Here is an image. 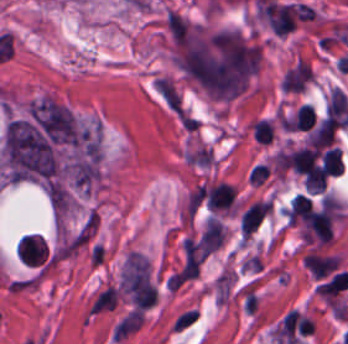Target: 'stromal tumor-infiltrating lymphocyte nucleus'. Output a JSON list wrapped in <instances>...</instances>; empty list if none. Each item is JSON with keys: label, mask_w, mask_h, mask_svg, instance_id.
Returning <instances> with one entry per match:
<instances>
[{"label": "stromal tumor-infiltrating lymphocyte nucleus", "mask_w": 348, "mask_h": 344, "mask_svg": "<svg viewBox=\"0 0 348 344\" xmlns=\"http://www.w3.org/2000/svg\"><path fill=\"white\" fill-rule=\"evenodd\" d=\"M253 137L260 143H268L273 138V126L266 118H258L252 128Z\"/></svg>", "instance_id": "obj_2"}, {"label": "stromal tumor-infiltrating lymphocyte nucleus", "mask_w": 348, "mask_h": 344, "mask_svg": "<svg viewBox=\"0 0 348 344\" xmlns=\"http://www.w3.org/2000/svg\"><path fill=\"white\" fill-rule=\"evenodd\" d=\"M316 115L313 105L307 103H300L292 120L291 128L294 129H309L314 125Z\"/></svg>", "instance_id": "obj_1"}]
</instances>
